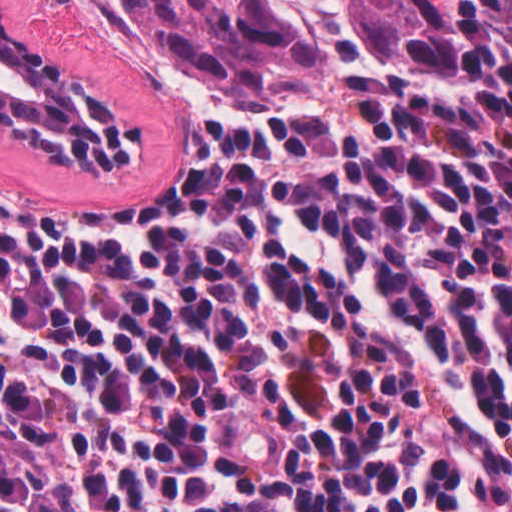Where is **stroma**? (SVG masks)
<instances>
[{
    "label": "stroma",
    "instance_id": "obj_1",
    "mask_svg": "<svg viewBox=\"0 0 512 512\" xmlns=\"http://www.w3.org/2000/svg\"><path fill=\"white\" fill-rule=\"evenodd\" d=\"M493 0H462L452 15L449 57L433 69H372L361 85L327 95H245L158 74L136 62L110 27L100 0H0L56 60L137 117L140 156L102 173L41 163L0 130V187L65 205L147 209L163 202L187 140L199 131L304 106L367 102L378 86L439 82L454 71L466 30Z\"/></svg>",
    "mask_w": 512,
    "mask_h": 512
}]
</instances>
